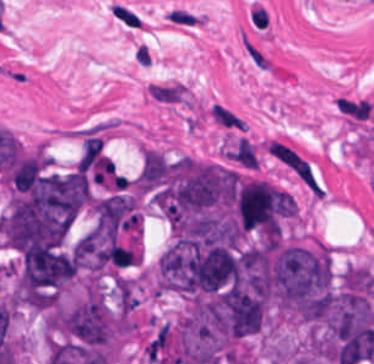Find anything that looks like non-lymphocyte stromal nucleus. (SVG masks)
<instances>
[{
    "label": "non-lymphocyte stromal nucleus",
    "mask_w": 374,
    "mask_h": 364,
    "mask_svg": "<svg viewBox=\"0 0 374 364\" xmlns=\"http://www.w3.org/2000/svg\"><path fill=\"white\" fill-rule=\"evenodd\" d=\"M241 45L252 66L261 71L279 73L280 70L271 53L243 29L241 32Z\"/></svg>",
    "instance_id": "1"
},
{
    "label": "non-lymphocyte stromal nucleus",
    "mask_w": 374,
    "mask_h": 364,
    "mask_svg": "<svg viewBox=\"0 0 374 364\" xmlns=\"http://www.w3.org/2000/svg\"><path fill=\"white\" fill-rule=\"evenodd\" d=\"M110 10L117 22L132 30H143L146 22L138 12L130 5L124 2L115 1Z\"/></svg>",
    "instance_id": "5"
},
{
    "label": "non-lymphocyte stromal nucleus",
    "mask_w": 374,
    "mask_h": 364,
    "mask_svg": "<svg viewBox=\"0 0 374 364\" xmlns=\"http://www.w3.org/2000/svg\"><path fill=\"white\" fill-rule=\"evenodd\" d=\"M210 116L213 122L227 129L240 130L244 123L236 112L221 103L213 104L210 110Z\"/></svg>",
    "instance_id": "6"
},
{
    "label": "non-lymphocyte stromal nucleus",
    "mask_w": 374,
    "mask_h": 364,
    "mask_svg": "<svg viewBox=\"0 0 374 364\" xmlns=\"http://www.w3.org/2000/svg\"><path fill=\"white\" fill-rule=\"evenodd\" d=\"M149 95L159 102L181 103L187 96V90L183 84L174 81L154 83L150 86Z\"/></svg>",
    "instance_id": "3"
},
{
    "label": "non-lymphocyte stromal nucleus",
    "mask_w": 374,
    "mask_h": 364,
    "mask_svg": "<svg viewBox=\"0 0 374 364\" xmlns=\"http://www.w3.org/2000/svg\"><path fill=\"white\" fill-rule=\"evenodd\" d=\"M225 156L240 170H254L259 159L258 149L240 135L227 145Z\"/></svg>",
    "instance_id": "2"
},
{
    "label": "non-lymphocyte stromal nucleus",
    "mask_w": 374,
    "mask_h": 364,
    "mask_svg": "<svg viewBox=\"0 0 374 364\" xmlns=\"http://www.w3.org/2000/svg\"><path fill=\"white\" fill-rule=\"evenodd\" d=\"M165 13L170 25L181 28H195L206 21L204 15L186 6H172Z\"/></svg>",
    "instance_id": "4"
}]
</instances>
